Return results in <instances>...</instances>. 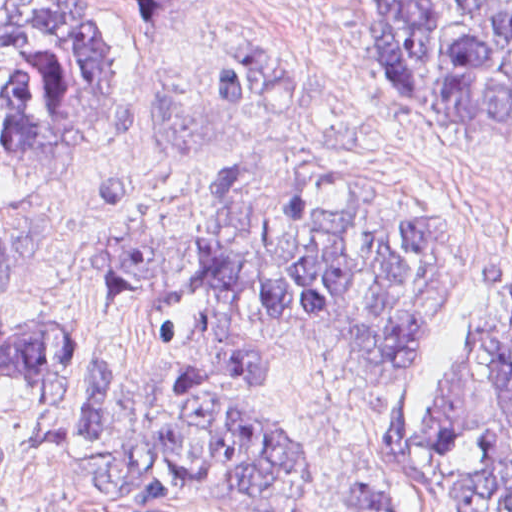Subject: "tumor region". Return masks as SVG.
<instances>
[{
    "label": "tumor region",
    "mask_w": 512,
    "mask_h": 512,
    "mask_svg": "<svg viewBox=\"0 0 512 512\" xmlns=\"http://www.w3.org/2000/svg\"><path fill=\"white\" fill-rule=\"evenodd\" d=\"M174 0H0V163H77L122 143L121 6ZM387 77L449 109L465 139L512 142V0H375ZM224 122L278 117L305 92L304 50L244 35L199 63ZM88 259L142 299L139 396L85 363V397L55 427L76 369L69 328L0 334V375L39 397L24 446L85 464L100 497L130 509L183 494L231 512H296L318 486L297 435L211 386L278 358L286 329L359 364L426 340L445 288L440 213L301 161H250L215 184L196 219L167 232L84 236ZM13 250L0 233V312ZM173 392V393H171ZM23 446V447H24ZM140 454L146 464L133 459ZM17 466L0 440V505ZM426 491L471 512H512V339L461 333L441 359L413 449ZM333 512H406L397 492L354 485Z\"/></svg>",
    "instance_id": "tumor-region-1"
}]
</instances>
